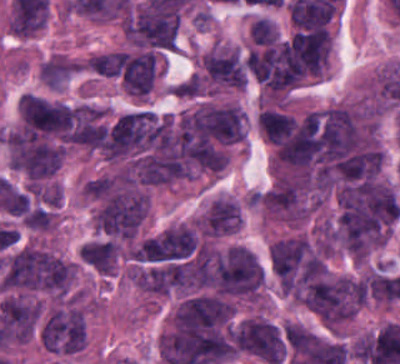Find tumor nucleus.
Here are the masks:
<instances>
[{"instance_id":"obj_4","label":"tumor nucleus","mask_w":400,"mask_h":364,"mask_svg":"<svg viewBox=\"0 0 400 364\" xmlns=\"http://www.w3.org/2000/svg\"><path fill=\"white\" fill-rule=\"evenodd\" d=\"M177 11L153 1H145L125 17L123 32L137 45L173 48Z\"/></svg>"},{"instance_id":"obj_3","label":"tumor nucleus","mask_w":400,"mask_h":364,"mask_svg":"<svg viewBox=\"0 0 400 364\" xmlns=\"http://www.w3.org/2000/svg\"><path fill=\"white\" fill-rule=\"evenodd\" d=\"M235 347L267 363L281 364L287 347L284 327L262 315H248L236 322Z\"/></svg>"},{"instance_id":"obj_1","label":"tumor nucleus","mask_w":400,"mask_h":364,"mask_svg":"<svg viewBox=\"0 0 400 364\" xmlns=\"http://www.w3.org/2000/svg\"><path fill=\"white\" fill-rule=\"evenodd\" d=\"M74 272L67 258L34 243L13 249L5 258L0 285L9 289L64 294Z\"/></svg>"},{"instance_id":"obj_7","label":"tumor nucleus","mask_w":400,"mask_h":364,"mask_svg":"<svg viewBox=\"0 0 400 364\" xmlns=\"http://www.w3.org/2000/svg\"><path fill=\"white\" fill-rule=\"evenodd\" d=\"M252 41L271 44L278 36L276 24L264 17H257L250 28Z\"/></svg>"},{"instance_id":"obj_5","label":"tumor nucleus","mask_w":400,"mask_h":364,"mask_svg":"<svg viewBox=\"0 0 400 364\" xmlns=\"http://www.w3.org/2000/svg\"><path fill=\"white\" fill-rule=\"evenodd\" d=\"M260 200L271 214L282 219L299 220L307 212L306 186L298 183H272Z\"/></svg>"},{"instance_id":"obj_6","label":"tumor nucleus","mask_w":400,"mask_h":364,"mask_svg":"<svg viewBox=\"0 0 400 364\" xmlns=\"http://www.w3.org/2000/svg\"><path fill=\"white\" fill-rule=\"evenodd\" d=\"M197 111L212 137L230 142L244 137V116L236 105L201 104Z\"/></svg>"},{"instance_id":"obj_2","label":"tumor nucleus","mask_w":400,"mask_h":364,"mask_svg":"<svg viewBox=\"0 0 400 364\" xmlns=\"http://www.w3.org/2000/svg\"><path fill=\"white\" fill-rule=\"evenodd\" d=\"M148 209V193L144 190L113 188L97 211V228L113 238H133Z\"/></svg>"}]
</instances>
